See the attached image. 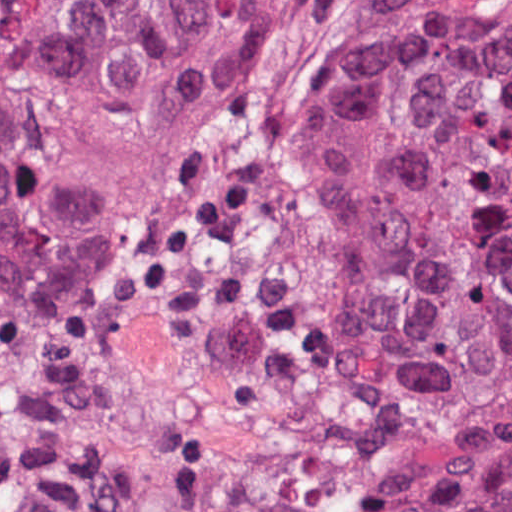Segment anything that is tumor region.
Here are the masks:
<instances>
[{
	"label": "tumor region",
	"instance_id": "1",
	"mask_svg": "<svg viewBox=\"0 0 512 512\" xmlns=\"http://www.w3.org/2000/svg\"><path fill=\"white\" fill-rule=\"evenodd\" d=\"M0 314L162 326L512 512V32L378 1H0Z\"/></svg>",
	"mask_w": 512,
	"mask_h": 512
}]
</instances>
